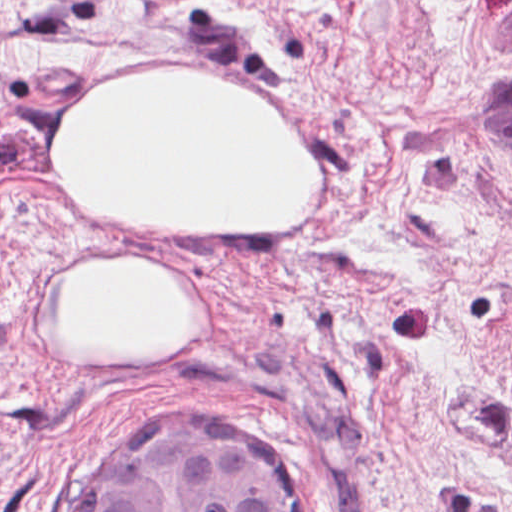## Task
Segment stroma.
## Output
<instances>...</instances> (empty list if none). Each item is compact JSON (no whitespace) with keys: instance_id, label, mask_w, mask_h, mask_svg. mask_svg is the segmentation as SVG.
<instances>
[{"instance_id":"obj_1","label":"stroma","mask_w":512,"mask_h":512,"mask_svg":"<svg viewBox=\"0 0 512 512\" xmlns=\"http://www.w3.org/2000/svg\"><path fill=\"white\" fill-rule=\"evenodd\" d=\"M150 77L263 100L302 220L150 242L77 211L40 128ZM126 266L167 271L188 340L60 347L50 304ZM151 419L244 441L313 512H512V0H0V512H99Z\"/></svg>"}]
</instances>
